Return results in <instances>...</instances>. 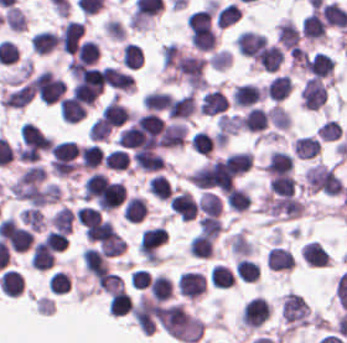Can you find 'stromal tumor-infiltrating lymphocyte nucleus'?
<instances>
[{
	"mask_svg": "<svg viewBox=\"0 0 347 343\" xmlns=\"http://www.w3.org/2000/svg\"><path fill=\"white\" fill-rule=\"evenodd\" d=\"M33 95L32 84L27 80L5 78L0 95L4 109H21L27 106Z\"/></svg>",
	"mask_w": 347,
	"mask_h": 343,
	"instance_id": "1",
	"label": "stromal tumor-infiltrating lymphocyte nucleus"
},
{
	"mask_svg": "<svg viewBox=\"0 0 347 343\" xmlns=\"http://www.w3.org/2000/svg\"><path fill=\"white\" fill-rule=\"evenodd\" d=\"M326 97L320 79L309 77L305 80L300 92V106L310 111H317Z\"/></svg>",
	"mask_w": 347,
	"mask_h": 343,
	"instance_id": "2",
	"label": "stromal tumor-infiltrating lymphocyte nucleus"
},
{
	"mask_svg": "<svg viewBox=\"0 0 347 343\" xmlns=\"http://www.w3.org/2000/svg\"><path fill=\"white\" fill-rule=\"evenodd\" d=\"M19 139L22 144L46 151L50 149L52 144L50 135L31 122L26 121L21 124Z\"/></svg>",
	"mask_w": 347,
	"mask_h": 343,
	"instance_id": "3",
	"label": "stromal tumor-infiltrating lymphocyte nucleus"
},
{
	"mask_svg": "<svg viewBox=\"0 0 347 343\" xmlns=\"http://www.w3.org/2000/svg\"><path fill=\"white\" fill-rule=\"evenodd\" d=\"M227 107V97L216 87L207 90L202 95L199 105V113L206 116H216L224 113Z\"/></svg>",
	"mask_w": 347,
	"mask_h": 343,
	"instance_id": "4",
	"label": "stromal tumor-infiltrating lymphocyte nucleus"
},
{
	"mask_svg": "<svg viewBox=\"0 0 347 343\" xmlns=\"http://www.w3.org/2000/svg\"><path fill=\"white\" fill-rule=\"evenodd\" d=\"M293 166L291 155L283 150L270 149L264 168V175L269 177L289 173Z\"/></svg>",
	"mask_w": 347,
	"mask_h": 343,
	"instance_id": "5",
	"label": "stromal tumor-infiltrating lymphocyte nucleus"
},
{
	"mask_svg": "<svg viewBox=\"0 0 347 343\" xmlns=\"http://www.w3.org/2000/svg\"><path fill=\"white\" fill-rule=\"evenodd\" d=\"M58 117L66 123H77L84 117L85 102L72 96H63L57 104Z\"/></svg>",
	"mask_w": 347,
	"mask_h": 343,
	"instance_id": "6",
	"label": "stromal tumor-infiltrating lymphocyte nucleus"
},
{
	"mask_svg": "<svg viewBox=\"0 0 347 343\" xmlns=\"http://www.w3.org/2000/svg\"><path fill=\"white\" fill-rule=\"evenodd\" d=\"M197 108L195 93L187 92L173 96L168 109V117L187 119Z\"/></svg>",
	"mask_w": 347,
	"mask_h": 343,
	"instance_id": "7",
	"label": "stromal tumor-infiltrating lymphocyte nucleus"
},
{
	"mask_svg": "<svg viewBox=\"0 0 347 343\" xmlns=\"http://www.w3.org/2000/svg\"><path fill=\"white\" fill-rule=\"evenodd\" d=\"M302 33L305 40L322 41L324 37L323 23L320 14L310 10L301 20Z\"/></svg>",
	"mask_w": 347,
	"mask_h": 343,
	"instance_id": "8",
	"label": "stromal tumor-infiltrating lymphocyte nucleus"
},
{
	"mask_svg": "<svg viewBox=\"0 0 347 343\" xmlns=\"http://www.w3.org/2000/svg\"><path fill=\"white\" fill-rule=\"evenodd\" d=\"M292 149L299 159H311L319 153V138L304 134L292 142Z\"/></svg>",
	"mask_w": 347,
	"mask_h": 343,
	"instance_id": "9",
	"label": "stromal tumor-infiltrating lymphocyte nucleus"
},
{
	"mask_svg": "<svg viewBox=\"0 0 347 343\" xmlns=\"http://www.w3.org/2000/svg\"><path fill=\"white\" fill-rule=\"evenodd\" d=\"M320 15L325 25L342 29L347 26V10L336 3H323Z\"/></svg>",
	"mask_w": 347,
	"mask_h": 343,
	"instance_id": "10",
	"label": "stromal tumor-infiltrating lymphocyte nucleus"
},
{
	"mask_svg": "<svg viewBox=\"0 0 347 343\" xmlns=\"http://www.w3.org/2000/svg\"><path fill=\"white\" fill-rule=\"evenodd\" d=\"M230 173L241 174L252 165L253 154L249 150H236L222 158Z\"/></svg>",
	"mask_w": 347,
	"mask_h": 343,
	"instance_id": "11",
	"label": "stromal tumor-infiltrating lymphocyte nucleus"
},
{
	"mask_svg": "<svg viewBox=\"0 0 347 343\" xmlns=\"http://www.w3.org/2000/svg\"><path fill=\"white\" fill-rule=\"evenodd\" d=\"M120 61L126 69L136 70L143 61L140 46L131 41H124L120 46Z\"/></svg>",
	"mask_w": 347,
	"mask_h": 343,
	"instance_id": "12",
	"label": "stromal tumor-infiltrating lymphocyte nucleus"
},
{
	"mask_svg": "<svg viewBox=\"0 0 347 343\" xmlns=\"http://www.w3.org/2000/svg\"><path fill=\"white\" fill-rule=\"evenodd\" d=\"M251 196L243 186H234L225 194V202L231 211H244L250 207Z\"/></svg>",
	"mask_w": 347,
	"mask_h": 343,
	"instance_id": "13",
	"label": "stromal tumor-infiltrating lymphocyte nucleus"
},
{
	"mask_svg": "<svg viewBox=\"0 0 347 343\" xmlns=\"http://www.w3.org/2000/svg\"><path fill=\"white\" fill-rule=\"evenodd\" d=\"M30 47L35 54H48L56 47V39L51 30H37L31 40Z\"/></svg>",
	"mask_w": 347,
	"mask_h": 343,
	"instance_id": "14",
	"label": "stromal tumor-infiltrating lymphocyte nucleus"
},
{
	"mask_svg": "<svg viewBox=\"0 0 347 343\" xmlns=\"http://www.w3.org/2000/svg\"><path fill=\"white\" fill-rule=\"evenodd\" d=\"M268 191L280 195H293L295 181L291 174H272L268 179Z\"/></svg>",
	"mask_w": 347,
	"mask_h": 343,
	"instance_id": "15",
	"label": "stromal tumor-infiltrating lymphocyte nucleus"
},
{
	"mask_svg": "<svg viewBox=\"0 0 347 343\" xmlns=\"http://www.w3.org/2000/svg\"><path fill=\"white\" fill-rule=\"evenodd\" d=\"M102 164L107 169L128 170L129 154L118 147L109 149L103 154Z\"/></svg>",
	"mask_w": 347,
	"mask_h": 343,
	"instance_id": "16",
	"label": "stromal tumor-infiltrating lymphocyte nucleus"
},
{
	"mask_svg": "<svg viewBox=\"0 0 347 343\" xmlns=\"http://www.w3.org/2000/svg\"><path fill=\"white\" fill-rule=\"evenodd\" d=\"M240 125V117L236 113H222L216 129L222 139H228L237 132Z\"/></svg>",
	"mask_w": 347,
	"mask_h": 343,
	"instance_id": "17",
	"label": "stromal tumor-infiltrating lymphocyte nucleus"
},
{
	"mask_svg": "<svg viewBox=\"0 0 347 343\" xmlns=\"http://www.w3.org/2000/svg\"><path fill=\"white\" fill-rule=\"evenodd\" d=\"M213 142L214 138L205 129H197L192 136L190 148L208 156Z\"/></svg>",
	"mask_w": 347,
	"mask_h": 343,
	"instance_id": "18",
	"label": "stromal tumor-infiltrating lymphocyte nucleus"
},
{
	"mask_svg": "<svg viewBox=\"0 0 347 343\" xmlns=\"http://www.w3.org/2000/svg\"><path fill=\"white\" fill-rule=\"evenodd\" d=\"M80 154L82 163L96 168L102 163V149L97 143L84 144L80 147Z\"/></svg>",
	"mask_w": 347,
	"mask_h": 343,
	"instance_id": "19",
	"label": "stromal tumor-infiltrating lymphocyte nucleus"
},
{
	"mask_svg": "<svg viewBox=\"0 0 347 343\" xmlns=\"http://www.w3.org/2000/svg\"><path fill=\"white\" fill-rule=\"evenodd\" d=\"M266 115L274 128L288 129L290 117L288 111L284 107L273 103Z\"/></svg>",
	"mask_w": 347,
	"mask_h": 343,
	"instance_id": "20",
	"label": "stromal tumor-infiltrating lymphocyte nucleus"
},
{
	"mask_svg": "<svg viewBox=\"0 0 347 343\" xmlns=\"http://www.w3.org/2000/svg\"><path fill=\"white\" fill-rule=\"evenodd\" d=\"M239 19V7L231 0L218 9L217 21L220 26H228Z\"/></svg>",
	"mask_w": 347,
	"mask_h": 343,
	"instance_id": "21",
	"label": "stromal tumor-infiltrating lymphocyte nucleus"
},
{
	"mask_svg": "<svg viewBox=\"0 0 347 343\" xmlns=\"http://www.w3.org/2000/svg\"><path fill=\"white\" fill-rule=\"evenodd\" d=\"M340 131L341 128L335 119L326 118L317 126L314 133L316 137L323 140H333L338 138Z\"/></svg>",
	"mask_w": 347,
	"mask_h": 343,
	"instance_id": "22",
	"label": "stromal tumor-infiltrating lymphocyte nucleus"
},
{
	"mask_svg": "<svg viewBox=\"0 0 347 343\" xmlns=\"http://www.w3.org/2000/svg\"><path fill=\"white\" fill-rule=\"evenodd\" d=\"M50 150L56 155L78 163V148L76 142L68 139L56 142Z\"/></svg>",
	"mask_w": 347,
	"mask_h": 343,
	"instance_id": "23",
	"label": "stromal tumor-infiltrating lymphocyte nucleus"
},
{
	"mask_svg": "<svg viewBox=\"0 0 347 343\" xmlns=\"http://www.w3.org/2000/svg\"><path fill=\"white\" fill-rule=\"evenodd\" d=\"M211 68L224 70L231 62V53L224 49L213 50L206 59Z\"/></svg>",
	"mask_w": 347,
	"mask_h": 343,
	"instance_id": "24",
	"label": "stromal tumor-infiltrating lymphocyte nucleus"
},
{
	"mask_svg": "<svg viewBox=\"0 0 347 343\" xmlns=\"http://www.w3.org/2000/svg\"><path fill=\"white\" fill-rule=\"evenodd\" d=\"M154 187L158 189H163V190H168V191H173V188L171 184L168 182V180L162 176L161 174H154L150 181H149Z\"/></svg>",
	"mask_w": 347,
	"mask_h": 343,
	"instance_id": "25",
	"label": "stromal tumor-infiltrating lymphocyte nucleus"
}]
</instances>
